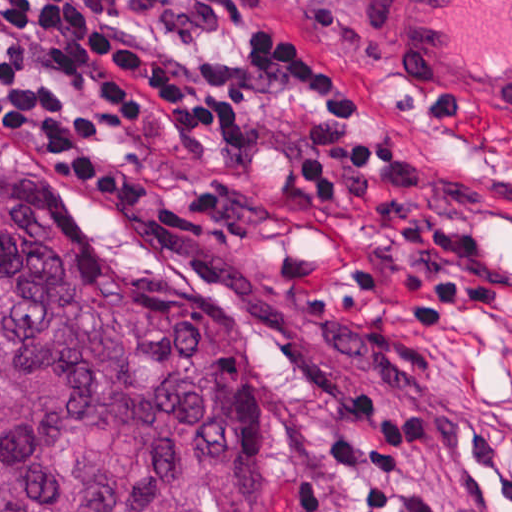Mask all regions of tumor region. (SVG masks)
I'll return each mask as SVG.
<instances>
[{
    "label": "tumor region",
    "instance_id": "e687c5a6",
    "mask_svg": "<svg viewBox=\"0 0 512 512\" xmlns=\"http://www.w3.org/2000/svg\"><path fill=\"white\" fill-rule=\"evenodd\" d=\"M245 325L0 141V512H250Z\"/></svg>",
    "mask_w": 512,
    "mask_h": 512
}]
</instances>
